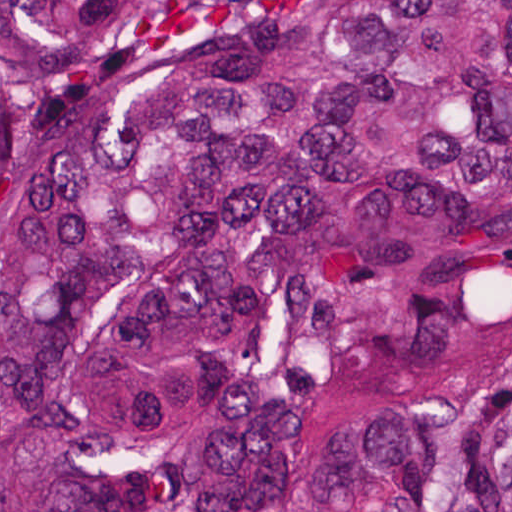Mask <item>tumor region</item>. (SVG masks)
Segmentation results:
<instances>
[{
  "instance_id": "1",
  "label": "tumor region",
  "mask_w": 512,
  "mask_h": 512,
  "mask_svg": "<svg viewBox=\"0 0 512 512\" xmlns=\"http://www.w3.org/2000/svg\"><path fill=\"white\" fill-rule=\"evenodd\" d=\"M0 512H512V0H0Z\"/></svg>"
}]
</instances>
